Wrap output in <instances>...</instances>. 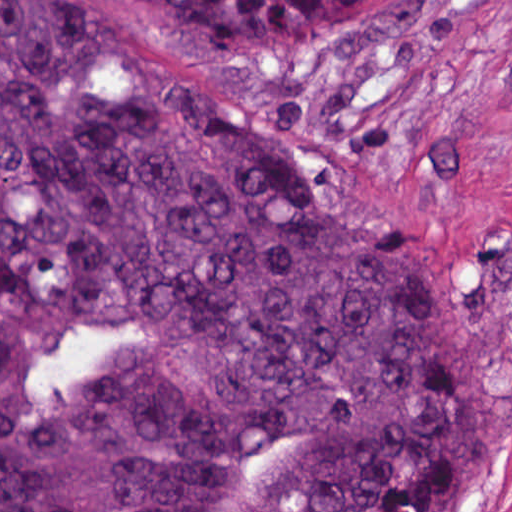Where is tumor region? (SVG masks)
I'll return each mask as SVG.
<instances>
[{
    "instance_id": "e687c5a6",
    "label": "tumor region",
    "mask_w": 512,
    "mask_h": 512,
    "mask_svg": "<svg viewBox=\"0 0 512 512\" xmlns=\"http://www.w3.org/2000/svg\"><path fill=\"white\" fill-rule=\"evenodd\" d=\"M334 49L401 0H135ZM478 294L125 0H0V512H472Z\"/></svg>"
}]
</instances>
